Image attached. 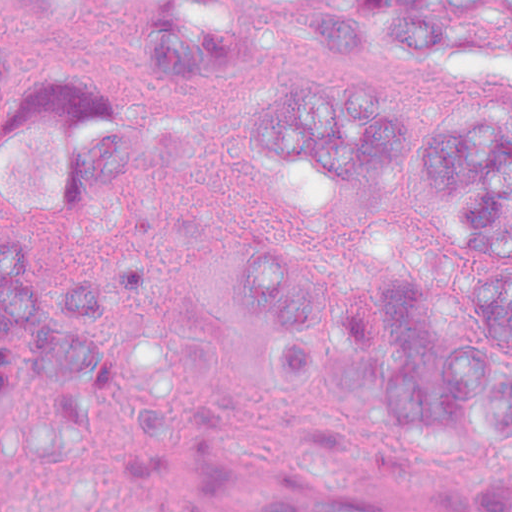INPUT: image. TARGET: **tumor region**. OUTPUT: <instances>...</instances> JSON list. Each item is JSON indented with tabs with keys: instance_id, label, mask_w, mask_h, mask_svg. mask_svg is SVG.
Returning a JSON list of instances; mask_svg holds the SVG:
<instances>
[{
	"instance_id": "obj_1",
	"label": "tumor region",
	"mask_w": 512,
	"mask_h": 512,
	"mask_svg": "<svg viewBox=\"0 0 512 512\" xmlns=\"http://www.w3.org/2000/svg\"><path fill=\"white\" fill-rule=\"evenodd\" d=\"M258 147L306 177L431 208L464 294L512 331V115L438 129L390 101L303 93L261 114ZM129 165L121 112L92 90L38 86L0 29V468H74L99 446L126 365L111 285L56 271L43 244Z\"/></svg>"
}]
</instances>
